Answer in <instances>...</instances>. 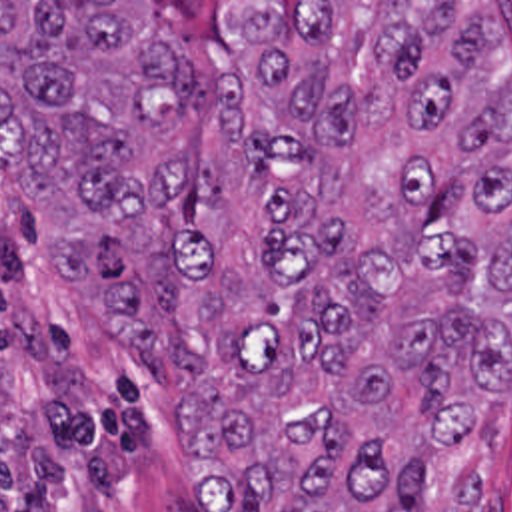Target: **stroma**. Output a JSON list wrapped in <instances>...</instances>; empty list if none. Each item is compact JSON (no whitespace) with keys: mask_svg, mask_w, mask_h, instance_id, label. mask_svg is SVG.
<instances>
[{"mask_svg":"<svg viewBox=\"0 0 512 512\" xmlns=\"http://www.w3.org/2000/svg\"><path fill=\"white\" fill-rule=\"evenodd\" d=\"M146 2L174 24L172 50L200 66L210 2H491L507 44L473 66L477 84L512 76V0H0ZM180 371L158 373L110 345L96 309L58 281V234L40 200L0 170V512L56 485L68 512H194V475L174 429ZM438 495L481 483L512 512V375L481 457L469 443L434 455Z\"/></svg>","mask_w":512,"mask_h":512,"instance_id":"obj_1","label":"stroma"}]
</instances>
